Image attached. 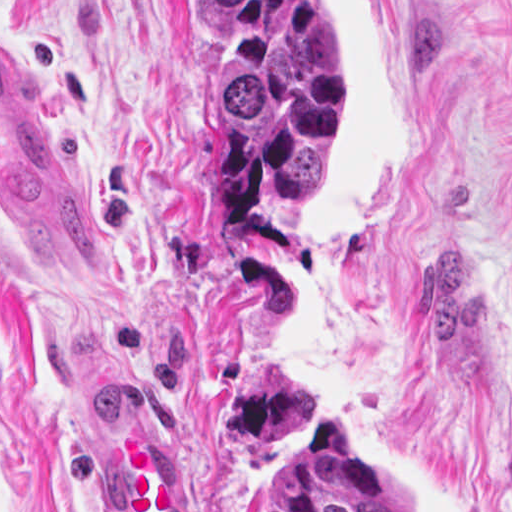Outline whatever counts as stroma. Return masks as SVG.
<instances>
[{"mask_svg":"<svg viewBox=\"0 0 512 512\" xmlns=\"http://www.w3.org/2000/svg\"><path fill=\"white\" fill-rule=\"evenodd\" d=\"M347 133V0H329ZM399 233L338 251L315 215L211 204L196 0H0L101 258L0 231V512H117L123 431L162 425L193 512L343 415L414 512H512V0H387Z\"/></svg>","mask_w":512,"mask_h":512,"instance_id":"35a3bbf8","label":"stroma"}]
</instances>
